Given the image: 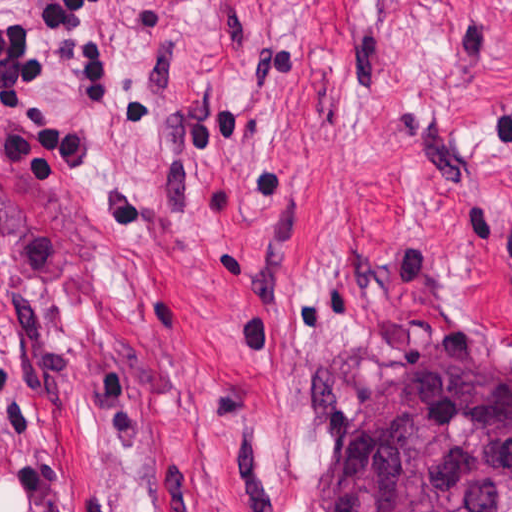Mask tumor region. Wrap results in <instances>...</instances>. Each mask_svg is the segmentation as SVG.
<instances>
[{"instance_id":"1","label":"tumor region","mask_w":512,"mask_h":512,"mask_svg":"<svg viewBox=\"0 0 512 512\" xmlns=\"http://www.w3.org/2000/svg\"><path fill=\"white\" fill-rule=\"evenodd\" d=\"M334 512H512V367L438 359L355 429Z\"/></svg>"}]
</instances>
